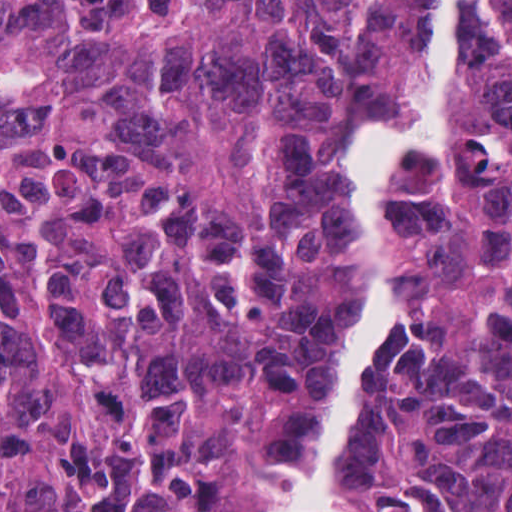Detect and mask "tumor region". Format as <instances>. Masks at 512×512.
Returning a JSON list of instances; mask_svg holds the SVG:
<instances>
[{
	"label": "tumor region",
	"mask_w": 512,
	"mask_h": 512,
	"mask_svg": "<svg viewBox=\"0 0 512 512\" xmlns=\"http://www.w3.org/2000/svg\"><path fill=\"white\" fill-rule=\"evenodd\" d=\"M512 16V0H503ZM430 0H0V512H259L366 292L340 167L407 135ZM413 326L325 512H512V52L395 193Z\"/></svg>",
	"instance_id": "tumor-region-1"
}]
</instances>
